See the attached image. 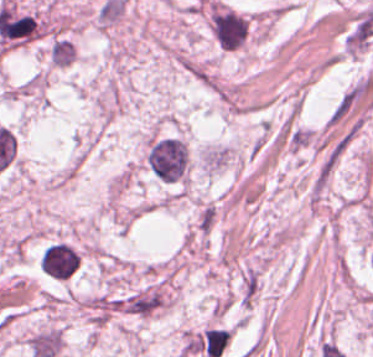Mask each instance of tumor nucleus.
<instances>
[{"instance_id": "obj_1", "label": "tumor nucleus", "mask_w": 373, "mask_h": 357, "mask_svg": "<svg viewBox=\"0 0 373 357\" xmlns=\"http://www.w3.org/2000/svg\"><path fill=\"white\" fill-rule=\"evenodd\" d=\"M144 162L159 181L183 182L188 178L190 155L179 135H153L146 145Z\"/></svg>"}, {"instance_id": "obj_2", "label": "tumor nucleus", "mask_w": 373, "mask_h": 357, "mask_svg": "<svg viewBox=\"0 0 373 357\" xmlns=\"http://www.w3.org/2000/svg\"><path fill=\"white\" fill-rule=\"evenodd\" d=\"M207 24L218 47L236 51L243 48L249 39L252 17L215 0L207 8Z\"/></svg>"}, {"instance_id": "obj_3", "label": "tumor nucleus", "mask_w": 373, "mask_h": 357, "mask_svg": "<svg viewBox=\"0 0 373 357\" xmlns=\"http://www.w3.org/2000/svg\"><path fill=\"white\" fill-rule=\"evenodd\" d=\"M78 253L69 242L51 241L40 253L39 268L55 279H67L77 268Z\"/></svg>"}]
</instances>
